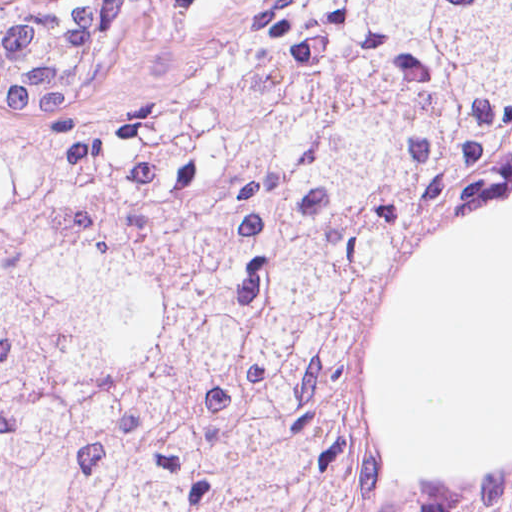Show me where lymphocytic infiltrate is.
<instances>
[{
	"instance_id": "obj_1",
	"label": "lymphocytic infiltrate",
	"mask_w": 512,
	"mask_h": 512,
	"mask_svg": "<svg viewBox=\"0 0 512 512\" xmlns=\"http://www.w3.org/2000/svg\"><path fill=\"white\" fill-rule=\"evenodd\" d=\"M225 38L228 47L237 34L245 18L256 0H216Z\"/></svg>"
}]
</instances>
